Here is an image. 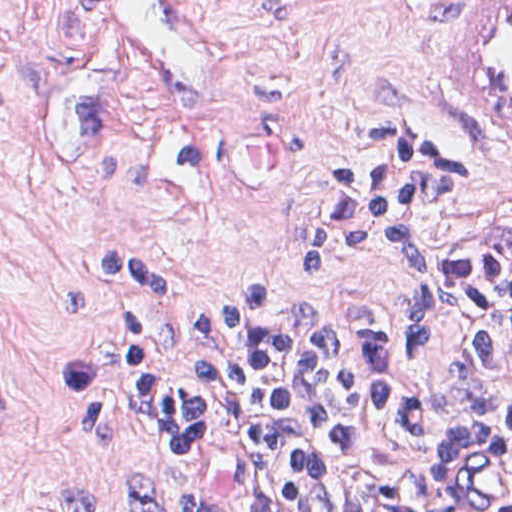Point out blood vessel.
I'll return each instance as SVG.
<instances>
[{
	"instance_id": "blood-vessel-1",
	"label": "blood vessel",
	"mask_w": 512,
	"mask_h": 512,
	"mask_svg": "<svg viewBox=\"0 0 512 512\" xmlns=\"http://www.w3.org/2000/svg\"><path fill=\"white\" fill-rule=\"evenodd\" d=\"M120 62L157 104L220 106L235 95L227 46L192 0H92ZM466 109L481 143L512 158V0H483L470 26Z\"/></svg>"
}]
</instances>
